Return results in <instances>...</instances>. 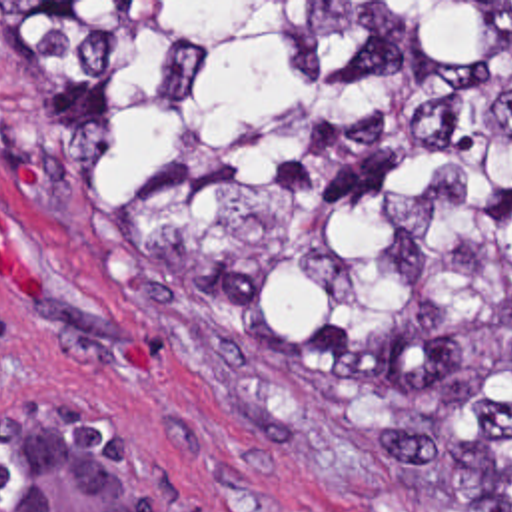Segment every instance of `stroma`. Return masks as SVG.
<instances>
[{
  "mask_svg": "<svg viewBox=\"0 0 512 512\" xmlns=\"http://www.w3.org/2000/svg\"><path fill=\"white\" fill-rule=\"evenodd\" d=\"M481 2V86L495 2L512 0H0ZM16 164L32 182H16ZM0 214L36 293L0 276V411L78 403L128 423L180 512H512L384 487L278 401L204 289L168 276L104 216L84 158L0 60ZM136 343L148 367H128Z\"/></svg>",
  "mask_w": 512,
  "mask_h": 512,
  "instance_id": "35a3bbf8",
  "label": "stroma"
}]
</instances>
